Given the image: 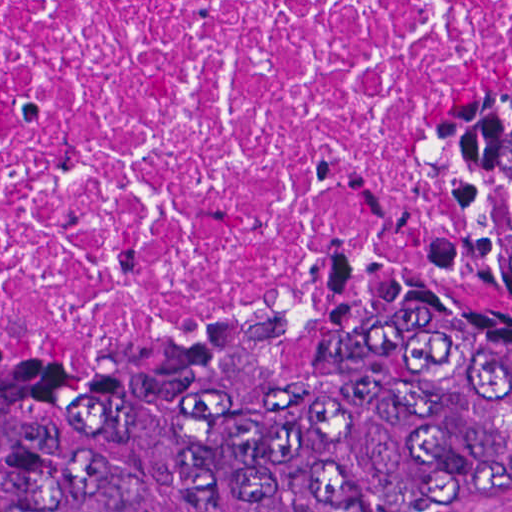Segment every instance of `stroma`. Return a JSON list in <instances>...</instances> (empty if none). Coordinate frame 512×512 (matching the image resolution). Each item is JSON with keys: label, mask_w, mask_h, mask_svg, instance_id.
Here are the masks:
<instances>
[{"label": "stroma", "mask_w": 512, "mask_h": 512, "mask_svg": "<svg viewBox=\"0 0 512 512\" xmlns=\"http://www.w3.org/2000/svg\"><path fill=\"white\" fill-rule=\"evenodd\" d=\"M512 93V58L482 104L449 136L426 167L347 221L303 228L188 343L152 351H100L77 356H2L16 365H144L178 358L256 313L289 279L327 249L403 211L448 165ZM480 512H512V500Z\"/></svg>", "instance_id": "stroma-1"}]
</instances>
